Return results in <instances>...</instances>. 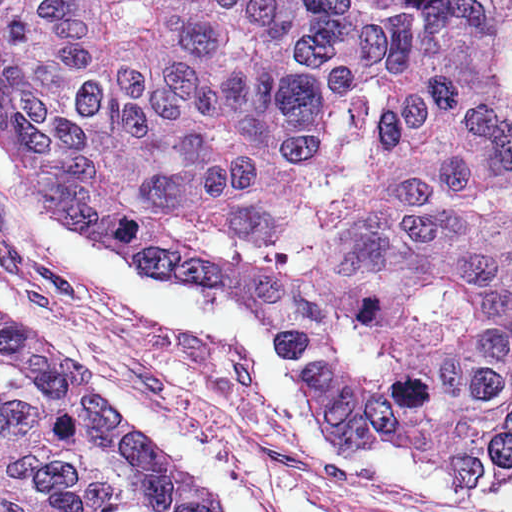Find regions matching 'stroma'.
<instances>
[{"instance_id": "35a3bbf8", "label": "stroma", "mask_w": 512, "mask_h": 512, "mask_svg": "<svg viewBox=\"0 0 512 512\" xmlns=\"http://www.w3.org/2000/svg\"><path fill=\"white\" fill-rule=\"evenodd\" d=\"M0 279L20 298L0 323L65 383L63 359L168 420L270 512H512V481L463 493L406 445L333 452L283 315L248 293L139 269L57 220L1 145Z\"/></svg>"}]
</instances>
